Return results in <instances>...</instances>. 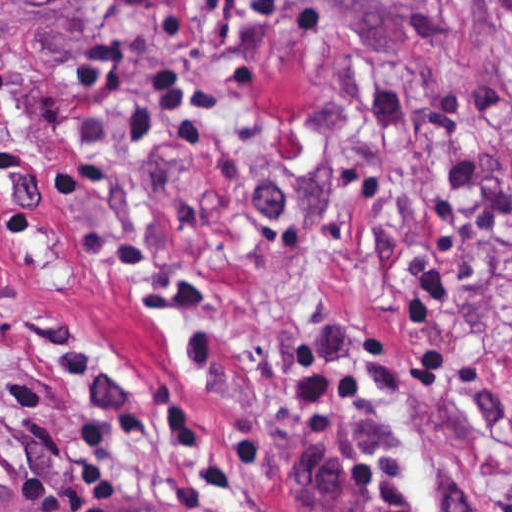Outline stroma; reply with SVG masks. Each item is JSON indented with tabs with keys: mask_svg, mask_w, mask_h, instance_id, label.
Wrapping results in <instances>:
<instances>
[{
	"mask_svg": "<svg viewBox=\"0 0 512 512\" xmlns=\"http://www.w3.org/2000/svg\"><path fill=\"white\" fill-rule=\"evenodd\" d=\"M0 328L64 512H512V0H0Z\"/></svg>",
	"mask_w": 512,
	"mask_h": 512,
	"instance_id": "stroma-1",
	"label": "stroma"
}]
</instances>
